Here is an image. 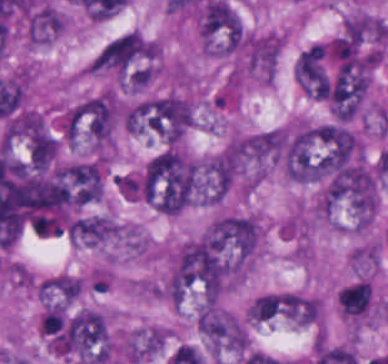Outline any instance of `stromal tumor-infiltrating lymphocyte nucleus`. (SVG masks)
Masks as SVG:
<instances>
[{"label":"stromal tumor-infiltrating lymphocyte nucleus","instance_id":"bc302bb0","mask_svg":"<svg viewBox=\"0 0 388 364\" xmlns=\"http://www.w3.org/2000/svg\"><path fill=\"white\" fill-rule=\"evenodd\" d=\"M336 300L342 313L357 320L366 316L372 305L371 285L353 281L338 291Z\"/></svg>","mask_w":388,"mask_h":364}]
</instances>
